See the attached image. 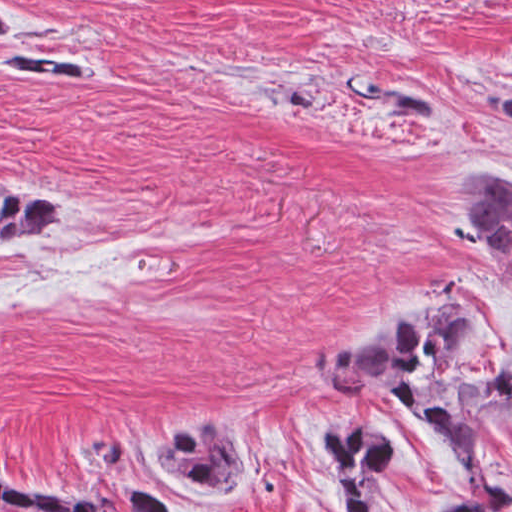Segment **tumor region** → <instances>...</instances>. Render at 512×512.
I'll return each mask as SVG.
<instances>
[{"mask_svg": "<svg viewBox=\"0 0 512 512\" xmlns=\"http://www.w3.org/2000/svg\"><path fill=\"white\" fill-rule=\"evenodd\" d=\"M23 32L20 14L1 0V34ZM33 46H1V70L29 73L74 90H103L109 73L86 61ZM378 95L399 113H434V101L410 80L360 78L343 96L356 103ZM470 110L484 129L512 135V76L476 81ZM455 194L473 239L512 268V170L479 169L459 176ZM56 223V199L8 185L1 194V240H34ZM313 381L365 397L387 391L422 418L449 453L467 491L432 512H508L512 489L491 479L486 447L512 427V315L493 316L460 287L421 284L345 330L323 340L308 362ZM323 426L309 457L336 512H380L379 490L397 461V442L376 423ZM104 464H124L127 440L100 423L79 446ZM175 488L228 498L256 467L251 448L224 429H185L148 458ZM1 476V512H108L88 494ZM129 512H180L132 484L120 494Z\"/></svg>", "mask_w": 512, "mask_h": 512, "instance_id": "e687c5a6", "label": "tumor region"}]
</instances>
